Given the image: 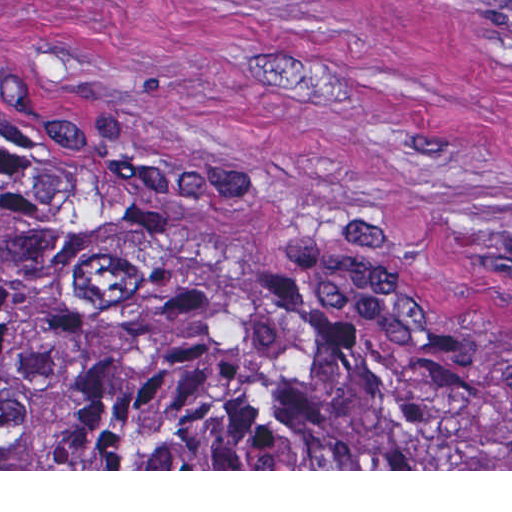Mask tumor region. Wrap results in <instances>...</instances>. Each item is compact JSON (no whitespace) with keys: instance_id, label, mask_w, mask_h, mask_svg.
<instances>
[{"instance_id":"1","label":"tumor region","mask_w":512,"mask_h":512,"mask_svg":"<svg viewBox=\"0 0 512 512\" xmlns=\"http://www.w3.org/2000/svg\"><path fill=\"white\" fill-rule=\"evenodd\" d=\"M0 469H512L473 351L275 280L195 199L0 121Z\"/></svg>"}]
</instances>
